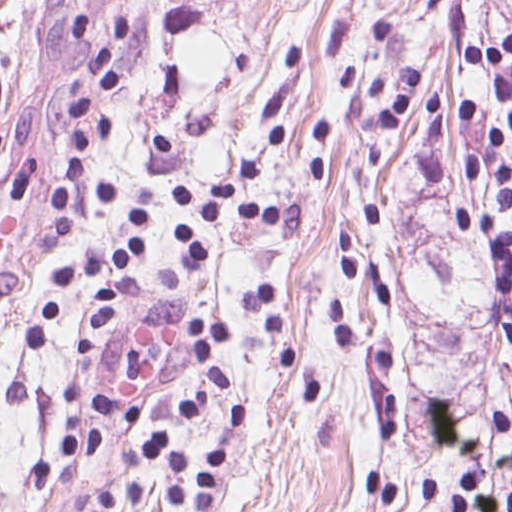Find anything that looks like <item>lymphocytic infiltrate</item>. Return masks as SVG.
<instances>
[{
  "label": "lymphocytic infiltrate",
  "instance_id": "f902f5d3",
  "mask_svg": "<svg viewBox=\"0 0 512 512\" xmlns=\"http://www.w3.org/2000/svg\"><path fill=\"white\" fill-rule=\"evenodd\" d=\"M129 33L130 24L123 20L111 39L102 43L89 63L79 70L66 97L72 145L62 161L52 199L56 242L69 240L79 213L81 190L87 186L96 189L99 200L107 208L112 199L110 185L94 166L92 149L112 136L113 119L112 116H87L92 106L84 97V84L96 79L101 89L122 85L114 64V52ZM462 61L470 71L491 79L506 108V118H496L483 104H472L466 112L468 123L488 135L484 144L464 163L465 178L498 199L494 208L485 213L466 209L454 211V224L489 250L494 287L512 291V226L505 225L501 217L512 209V158L507 157L505 149L507 134H512V33L491 40H468L462 48ZM282 139L273 131L265 136L213 197L201 199L194 195L192 185H179L177 197L189 215L177 233L183 248L191 255L202 256L198 231L212 224L261 222L290 240L303 238L305 213L297 204L249 199L253 189L263 184L265 163L279 148ZM147 224L148 211L141 207L136 237L128 250L73 259L60 266L48 309L30 324L26 333L32 345L43 347L45 336L53 329L55 318L76 283L86 281L93 288V303L79 353L91 357L104 328L114 319L120 294L114 284L104 282L102 273L119 272L140 261V229ZM226 332L224 324L208 322L200 313L191 317L186 330L201 357V370L226 390H232V382L217 361L218 343ZM498 336L512 345V316L500 325ZM226 448L227 441L221 439L210 445L206 478L201 488L191 491L190 461L172 449L170 439L160 433H149L143 441V454L171 473L165 491L167 503L193 512H211L222 479ZM417 487L435 512H512V484L505 491H492L482 472L461 471L452 475L456 496L448 500L443 484L434 477L423 475ZM163 506L164 496L156 488L136 481H119L101 485L88 503L70 512H125L126 509L158 512Z\"/></svg>",
  "mask_w": 512,
  "mask_h": 512
}]
</instances>
